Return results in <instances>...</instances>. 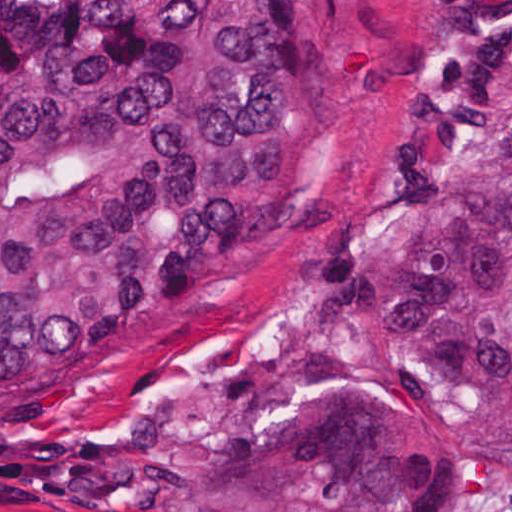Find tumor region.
<instances>
[{
	"mask_svg": "<svg viewBox=\"0 0 512 512\" xmlns=\"http://www.w3.org/2000/svg\"><path fill=\"white\" fill-rule=\"evenodd\" d=\"M297 0H0V394L202 295L282 190ZM345 342L245 354L166 424L0 431L85 512H438L512 477V0H449L325 228Z\"/></svg>",
	"mask_w": 512,
	"mask_h": 512,
	"instance_id": "e687c5a6",
	"label": "tumor region"
}]
</instances>
